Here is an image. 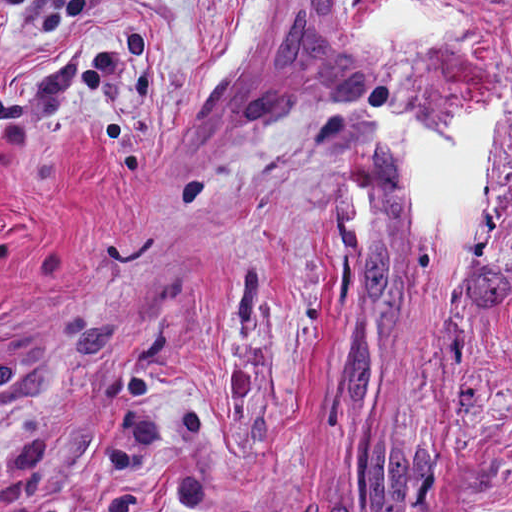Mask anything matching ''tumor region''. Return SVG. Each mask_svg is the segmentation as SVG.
Masks as SVG:
<instances>
[{
    "label": "tumor region",
    "mask_w": 512,
    "mask_h": 512,
    "mask_svg": "<svg viewBox=\"0 0 512 512\" xmlns=\"http://www.w3.org/2000/svg\"><path fill=\"white\" fill-rule=\"evenodd\" d=\"M377 93H378V85L372 90V92L369 94V96L358 103L350 104V105H344L340 107H360V106H367L376 104L377 101ZM205 158H228V157H236L240 155H204Z\"/></svg>",
    "instance_id": "1"
}]
</instances>
